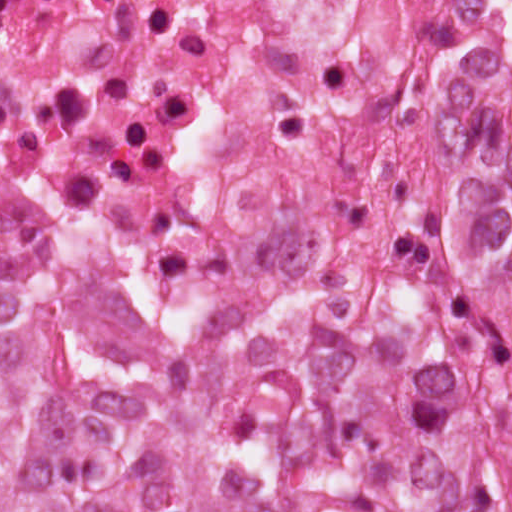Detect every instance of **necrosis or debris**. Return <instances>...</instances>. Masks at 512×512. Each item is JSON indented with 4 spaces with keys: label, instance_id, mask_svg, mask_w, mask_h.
Masks as SVG:
<instances>
[{
    "label": "necrosis or debris",
    "instance_id": "1",
    "mask_svg": "<svg viewBox=\"0 0 512 512\" xmlns=\"http://www.w3.org/2000/svg\"><path fill=\"white\" fill-rule=\"evenodd\" d=\"M512 194V0H0V275L94 214L419 261Z\"/></svg>",
    "mask_w": 512,
    "mask_h": 512
}]
</instances>
